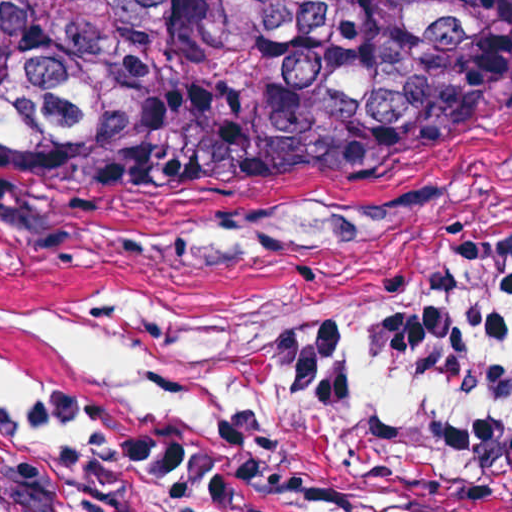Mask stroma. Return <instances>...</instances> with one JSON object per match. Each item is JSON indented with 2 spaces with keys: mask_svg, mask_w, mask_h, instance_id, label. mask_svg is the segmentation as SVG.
<instances>
[{
  "mask_svg": "<svg viewBox=\"0 0 512 512\" xmlns=\"http://www.w3.org/2000/svg\"><path fill=\"white\" fill-rule=\"evenodd\" d=\"M484 236H512V124L244 241L0 196L3 336L180 333L241 389L230 420L0 414V512H489L397 464L383 436L419 409H504L419 377H389L360 405H307L255 368L315 312L401 309L445 253Z\"/></svg>",
  "mask_w": 512,
  "mask_h": 512,
  "instance_id": "stroma-1",
  "label": "stroma"
}]
</instances>
